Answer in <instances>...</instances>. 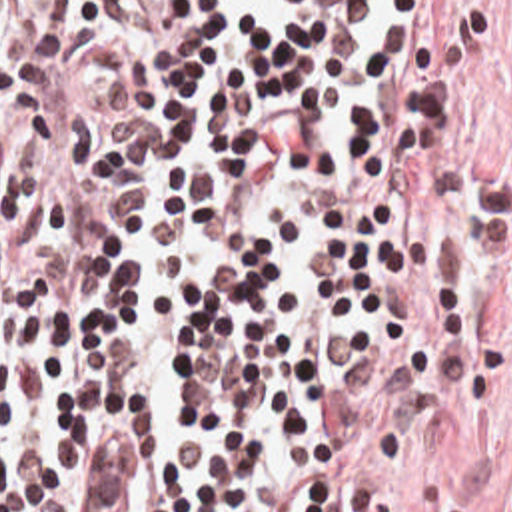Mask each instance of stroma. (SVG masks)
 Here are the masks:
<instances>
[{
  "mask_svg": "<svg viewBox=\"0 0 512 512\" xmlns=\"http://www.w3.org/2000/svg\"><path fill=\"white\" fill-rule=\"evenodd\" d=\"M461 2L481 42L475 126L491 242L455 366L397 439L366 512H512V0Z\"/></svg>",
  "mask_w": 512,
  "mask_h": 512,
  "instance_id": "1",
  "label": "stroma"
}]
</instances>
